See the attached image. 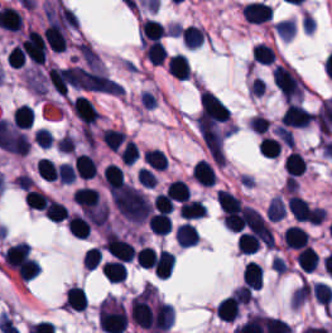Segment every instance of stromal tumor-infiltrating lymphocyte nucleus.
<instances>
[{
  "mask_svg": "<svg viewBox=\"0 0 332 333\" xmlns=\"http://www.w3.org/2000/svg\"><path fill=\"white\" fill-rule=\"evenodd\" d=\"M37 171L42 179L49 181L58 176V168L55 162L43 156L37 165Z\"/></svg>",
  "mask_w": 332,
  "mask_h": 333,
  "instance_id": "obj_24",
  "label": "stromal tumor-infiltrating lymphocyte nucleus"
},
{
  "mask_svg": "<svg viewBox=\"0 0 332 333\" xmlns=\"http://www.w3.org/2000/svg\"><path fill=\"white\" fill-rule=\"evenodd\" d=\"M174 238L179 246H192L198 241V233L190 221L178 223Z\"/></svg>",
  "mask_w": 332,
  "mask_h": 333,
  "instance_id": "obj_7",
  "label": "stromal tumor-infiltrating lymphocyte nucleus"
},
{
  "mask_svg": "<svg viewBox=\"0 0 332 333\" xmlns=\"http://www.w3.org/2000/svg\"><path fill=\"white\" fill-rule=\"evenodd\" d=\"M102 140L110 149H117L125 134L116 127H102L101 129Z\"/></svg>",
  "mask_w": 332,
  "mask_h": 333,
  "instance_id": "obj_22",
  "label": "stromal tumor-infiltrating lymphocyte nucleus"
},
{
  "mask_svg": "<svg viewBox=\"0 0 332 333\" xmlns=\"http://www.w3.org/2000/svg\"><path fill=\"white\" fill-rule=\"evenodd\" d=\"M314 112L305 108L297 102H290L284 109L280 118L283 126H304L309 123Z\"/></svg>",
  "mask_w": 332,
  "mask_h": 333,
  "instance_id": "obj_2",
  "label": "stromal tumor-infiltrating lymphocyte nucleus"
},
{
  "mask_svg": "<svg viewBox=\"0 0 332 333\" xmlns=\"http://www.w3.org/2000/svg\"><path fill=\"white\" fill-rule=\"evenodd\" d=\"M70 102L77 116L86 126L96 121L98 112L87 96L77 95Z\"/></svg>",
  "mask_w": 332,
  "mask_h": 333,
  "instance_id": "obj_4",
  "label": "stromal tumor-infiltrating lymphocyte nucleus"
},
{
  "mask_svg": "<svg viewBox=\"0 0 332 333\" xmlns=\"http://www.w3.org/2000/svg\"><path fill=\"white\" fill-rule=\"evenodd\" d=\"M87 305V297L82 286L70 285L64 296L63 306L66 308L84 309Z\"/></svg>",
  "mask_w": 332,
  "mask_h": 333,
  "instance_id": "obj_9",
  "label": "stromal tumor-infiltrating lymphocyte nucleus"
},
{
  "mask_svg": "<svg viewBox=\"0 0 332 333\" xmlns=\"http://www.w3.org/2000/svg\"><path fill=\"white\" fill-rule=\"evenodd\" d=\"M101 274L110 281L121 280L125 274L120 260H106L100 264Z\"/></svg>",
  "mask_w": 332,
  "mask_h": 333,
  "instance_id": "obj_20",
  "label": "stromal tumor-infiltrating lymphocyte nucleus"
},
{
  "mask_svg": "<svg viewBox=\"0 0 332 333\" xmlns=\"http://www.w3.org/2000/svg\"><path fill=\"white\" fill-rule=\"evenodd\" d=\"M282 165L284 171L290 178L296 176L300 174L304 168L302 155L290 150L285 154Z\"/></svg>",
  "mask_w": 332,
  "mask_h": 333,
  "instance_id": "obj_15",
  "label": "stromal tumor-infiltrating lymphocyte nucleus"
},
{
  "mask_svg": "<svg viewBox=\"0 0 332 333\" xmlns=\"http://www.w3.org/2000/svg\"><path fill=\"white\" fill-rule=\"evenodd\" d=\"M150 231L155 234H166L172 228L169 213L157 212L147 218Z\"/></svg>",
  "mask_w": 332,
  "mask_h": 333,
  "instance_id": "obj_16",
  "label": "stromal tumor-infiltrating lymphocyte nucleus"
},
{
  "mask_svg": "<svg viewBox=\"0 0 332 333\" xmlns=\"http://www.w3.org/2000/svg\"><path fill=\"white\" fill-rule=\"evenodd\" d=\"M168 72L176 79H188L189 66L182 53H174L165 63Z\"/></svg>",
  "mask_w": 332,
  "mask_h": 333,
  "instance_id": "obj_6",
  "label": "stromal tumor-infiltrating lymphocyte nucleus"
},
{
  "mask_svg": "<svg viewBox=\"0 0 332 333\" xmlns=\"http://www.w3.org/2000/svg\"><path fill=\"white\" fill-rule=\"evenodd\" d=\"M43 209H44L46 218H48L52 221L59 222L68 215L63 204L56 201L55 199L48 198Z\"/></svg>",
  "mask_w": 332,
  "mask_h": 333,
  "instance_id": "obj_21",
  "label": "stromal tumor-infiltrating lymphocyte nucleus"
},
{
  "mask_svg": "<svg viewBox=\"0 0 332 333\" xmlns=\"http://www.w3.org/2000/svg\"><path fill=\"white\" fill-rule=\"evenodd\" d=\"M296 260L300 268L310 271L317 265L318 256L310 244H303L298 249Z\"/></svg>",
  "mask_w": 332,
  "mask_h": 333,
  "instance_id": "obj_14",
  "label": "stromal tumor-infiltrating lymphocyte nucleus"
},
{
  "mask_svg": "<svg viewBox=\"0 0 332 333\" xmlns=\"http://www.w3.org/2000/svg\"><path fill=\"white\" fill-rule=\"evenodd\" d=\"M272 80L284 99L299 97L304 84L296 73L283 63H275L272 68Z\"/></svg>",
  "mask_w": 332,
  "mask_h": 333,
  "instance_id": "obj_1",
  "label": "stromal tumor-infiltrating lymphocyte nucleus"
},
{
  "mask_svg": "<svg viewBox=\"0 0 332 333\" xmlns=\"http://www.w3.org/2000/svg\"><path fill=\"white\" fill-rule=\"evenodd\" d=\"M192 178L202 185H213L215 172L206 159H199L191 169Z\"/></svg>",
  "mask_w": 332,
  "mask_h": 333,
  "instance_id": "obj_10",
  "label": "stromal tumor-infiltrating lymphocyte nucleus"
},
{
  "mask_svg": "<svg viewBox=\"0 0 332 333\" xmlns=\"http://www.w3.org/2000/svg\"><path fill=\"white\" fill-rule=\"evenodd\" d=\"M306 235L302 226L288 225L284 228L283 245L297 250L303 245Z\"/></svg>",
  "mask_w": 332,
  "mask_h": 333,
  "instance_id": "obj_12",
  "label": "stromal tumor-infiltrating lymphocyte nucleus"
},
{
  "mask_svg": "<svg viewBox=\"0 0 332 333\" xmlns=\"http://www.w3.org/2000/svg\"><path fill=\"white\" fill-rule=\"evenodd\" d=\"M178 210L181 217L191 219L201 217L206 212L202 202L197 198H189L182 202Z\"/></svg>",
  "mask_w": 332,
  "mask_h": 333,
  "instance_id": "obj_18",
  "label": "stromal tumor-infiltrating lymphocyte nucleus"
},
{
  "mask_svg": "<svg viewBox=\"0 0 332 333\" xmlns=\"http://www.w3.org/2000/svg\"><path fill=\"white\" fill-rule=\"evenodd\" d=\"M147 164L155 169H164L166 166V158L164 151L156 148H149L143 153Z\"/></svg>",
  "mask_w": 332,
  "mask_h": 333,
  "instance_id": "obj_25",
  "label": "stromal tumor-infiltrating lymphocyte nucleus"
},
{
  "mask_svg": "<svg viewBox=\"0 0 332 333\" xmlns=\"http://www.w3.org/2000/svg\"><path fill=\"white\" fill-rule=\"evenodd\" d=\"M270 6L264 1L253 0L241 5V16L251 24H259L270 17Z\"/></svg>",
  "mask_w": 332,
  "mask_h": 333,
  "instance_id": "obj_3",
  "label": "stromal tumor-infiltrating lymphocyte nucleus"
},
{
  "mask_svg": "<svg viewBox=\"0 0 332 333\" xmlns=\"http://www.w3.org/2000/svg\"><path fill=\"white\" fill-rule=\"evenodd\" d=\"M189 187L180 179H173L164 189L168 199L183 201L188 199Z\"/></svg>",
  "mask_w": 332,
  "mask_h": 333,
  "instance_id": "obj_19",
  "label": "stromal tumor-infiltrating lymphocyte nucleus"
},
{
  "mask_svg": "<svg viewBox=\"0 0 332 333\" xmlns=\"http://www.w3.org/2000/svg\"><path fill=\"white\" fill-rule=\"evenodd\" d=\"M11 120L20 127L30 126L33 122V107L22 102L11 112Z\"/></svg>",
  "mask_w": 332,
  "mask_h": 333,
  "instance_id": "obj_17",
  "label": "stromal tumor-infiltrating lymphocyte nucleus"
},
{
  "mask_svg": "<svg viewBox=\"0 0 332 333\" xmlns=\"http://www.w3.org/2000/svg\"><path fill=\"white\" fill-rule=\"evenodd\" d=\"M241 280L246 287L257 289L261 285L260 265L254 260H246L241 272Z\"/></svg>",
  "mask_w": 332,
  "mask_h": 333,
  "instance_id": "obj_8",
  "label": "stromal tumor-infiltrating lymphocyte nucleus"
},
{
  "mask_svg": "<svg viewBox=\"0 0 332 333\" xmlns=\"http://www.w3.org/2000/svg\"><path fill=\"white\" fill-rule=\"evenodd\" d=\"M102 179L106 189L110 192L124 180V174L116 163L108 162L101 169Z\"/></svg>",
  "mask_w": 332,
  "mask_h": 333,
  "instance_id": "obj_11",
  "label": "stromal tumor-infiltrating lymphocyte nucleus"
},
{
  "mask_svg": "<svg viewBox=\"0 0 332 333\" xmlns=\"http://www.w3.org/2000/svg\"><path fill=\"white\" fill-rule=\"evenodd\" d=\"M165 28L163 24L156 19H143L140 21L139 35L140 41L145 43L156 40L161 37Z\"/></svg>",
  "mask_w": 332,
  "mask_h": 333,
  "instance_id": "obj_5",
  "label": "stromal tumor-infiltrating lymphocyte nucleus"
},
{
  "mask_svg": "<svg viewBox=\"0 0 332 333\" xmlns=\"http://www.w3.org/2000/svg\"><path fill=\"white\" fill-rule=\"evenodd\" d=\"M275 53L273 48L266 44L254 43L251 49V58L258 63H271Z\"/></svg>",
  "mask_w": 332,
  "mask_h": 333,
  "instance_id": "obj_23",
  "label": "stromal tumor-infiltrating lymphocyte nucleus"
},
{
  "mask_svg": "<svg viewBox=\"0 0 332 333\" xmlns=\"http://www.w3.org/2000/svg\"><path fill=\"white\" fill-rule=\"evenodd\" d=\"M72 168L81 178H89L96 173V167L89 154H76Z\"/></svg>",
  "mask_w": 332,
  "mask_h": 333,
  "instance_id": "obj_13",
  "label": "stromal tumor-infiltrating lymphocyte nucleus"
}]
</instances>
